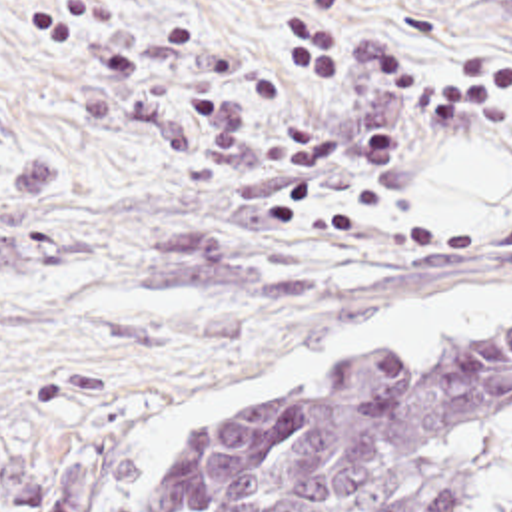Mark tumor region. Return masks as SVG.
<instances>
[{"label":"tumor region","mask_w":512,"mask_h":512,"mask_svg":"<svg viewBox=\"0 0 512 512\" xmlns=\"http://www.w3.org/2000/svg\"><path fill=\"white\" fill-rule=\"evenodd\" d=\"M154 512H512V323L276 384Z\"/></svg>","instance_id":"e687c5a6"}]
</instances>
